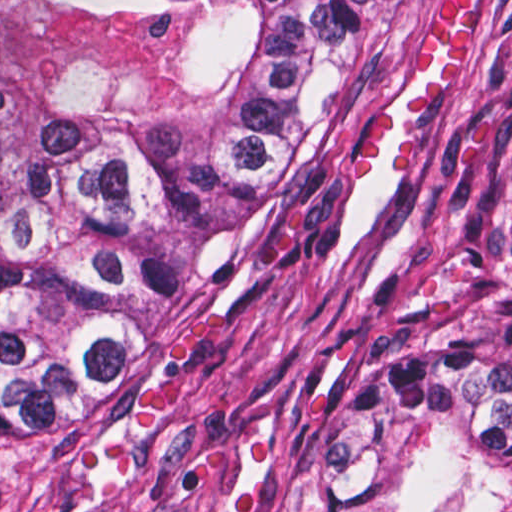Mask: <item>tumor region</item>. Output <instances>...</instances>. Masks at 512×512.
Segmentation results:
<instances>
[{"label":"tumor region","instance_id":"tumor-region-1","mask_svg":"<svg viewBox=\"0 0 512 512\" xmlns=\"http://www.w3.org/2000/svg\"><path fill=\"white\" fill-rule=\"evenodd\" d=\"M367 0H0V494L89 459L341 121ZM330 512H512V291L331 438Z\"/></svg>","mask_w":512,"mask_h":512}]
</instances>
